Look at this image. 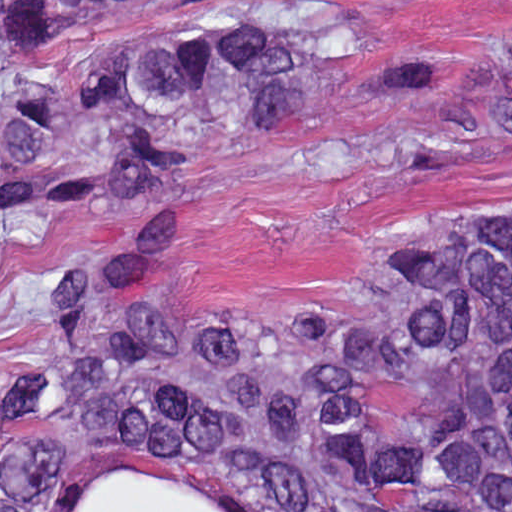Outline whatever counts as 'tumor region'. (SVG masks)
<instances>
[{"label": "tumor region", "instance_id": "obj_1", "mask_svg": "<svg viewBox=\"0 0 512 512\" xmlns=\"http://www.w3.org/2000/svg\"><path fill=\"white\" fill-rule=\"evenodd\" d=\"M249 1L1 0V244L110 178L170 214L116 216L62 268L1 421V512H56L62 428L250 477L277 512H367L382 482L512 500V184L415 235L357 312L160 321L186 242L183 168L240 133L328 115L335 68L356 56L334 18L105 43L69 92L24 72L28 54L115 13ZM481 70L445 116L453 144L512 141V92Z\"/></svg>", "mask_w": 512, "mask_h": 512}]
</instances>
